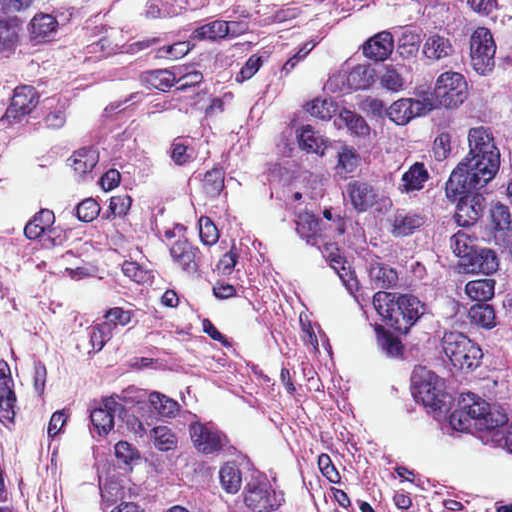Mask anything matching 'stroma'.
I'll return each instance as SVG.
<instances>
[{
    "mask_svg": "<svg viewBox=\"0 0 512 512\" xmlns=\"http://www.w3.org/2000/svg\"><path fill=\"white\" fill-rule=\"evenodd\" d=\"M362 2L101 0L0 46V154L80 89L149 80L84 134L75 214L0 233V440L19 512H62L61 402L140 346L246 378L287 418L333 512H512L377 443L230 182L232 151L293 60Z\"/></svg>",
    "mask_w": 512,
    "mask_h": 512,
    "instance_id": "obj_1",
    "label": "stroma"
}]
</instances>
